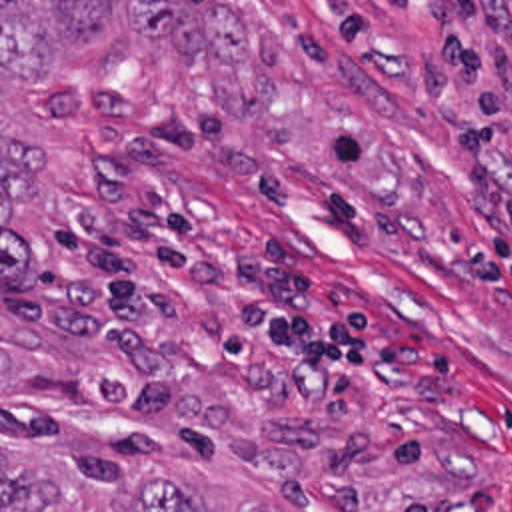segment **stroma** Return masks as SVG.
Masks as SVG:
<instances>
[{
	"instance_id": "obj_1",
	"label": "stroma",
	"mask_w": 512,
	"mask_h": 512,
	"mask_svg": "<svg viewBox=\"0 0 512 512\" xmlns=\"http://www.w3.org/2000/svg\"><path fill=\"white\" fill-rule=\"evenodd\" d=\"M218 2L230 70L116 16L0 132V441L178 479L200 512H512V0Z\"/></svg>"
}]
</instances>
